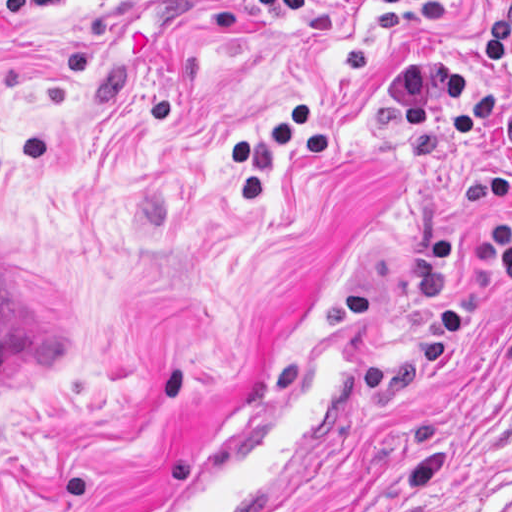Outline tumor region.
Here are the masks:
<instances>
[{"mask_svg":"<svg viewBox=\"0 0 512 512\" xmlns=\"http://www.w3.org/2000/svg\"><path fill=\"white\" fill-rule=\"evenodd\" d=\"M89 344V307L70 283L1 256V385L61 372Z\"/></svg>","mask_w":512,"mask_h":512,"instance_id":"1","label":"tumor region"}]
</instances>
